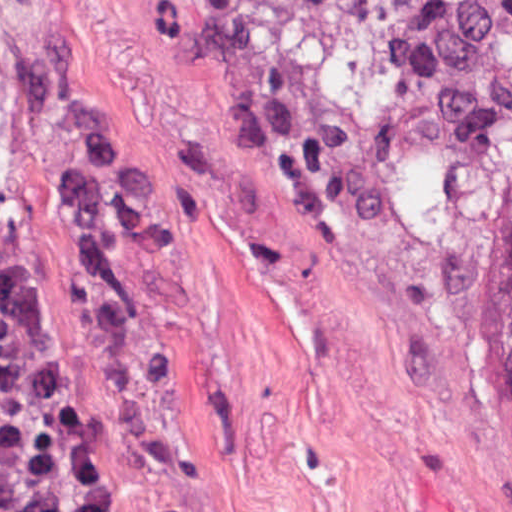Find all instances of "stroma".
I'll use <instances>...</instances> for the list:
<instances>
[{
	"mask_svg": "<svg viewBox=\"0 0 512 512\" xmlns=\"http://www.w3.org/2000/svg\"><path fill=\"white\" fill-rule=\"evenodd\" d=\"M0 201L99 512H512L483 295L241 0H0Z\"/></svg>",
	"mask_w": 512,
	"mask_h": 512,
	"instance_id": "1",
	"label": "stroma"
}]
</instances>
